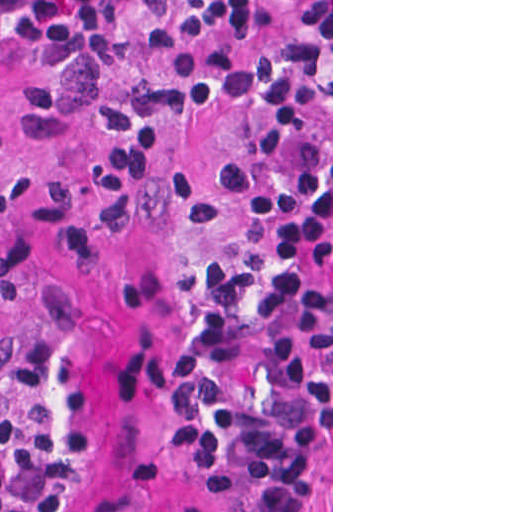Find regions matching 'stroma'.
I'll list each match as a JSON object with an SVG mask.
<instances>
[{
	"mask_svg": "<svg viewBox=\"0 0 512 512\" xmlns=\"http://www.w3.org/2000/svg\"><path fill=\"white\" fill-rule=\"evenodd\" d=\"M16 1L0 0V11ZM283 33L321 51L331 113V438L314 460L302 512H333V0H291L250 48L213 51L186 67L161 175L121 232L22 246L0 260V360L28 333L53 331L70 379L103 407L57 512H219L206 479L184 471L165 445L170 336L202 274L240 254L254 141L235 105L237 58ZM100 127L98 76L37 70L0 89V157L27 172L76 170Z\"/></svg>",
	"mask_w": 512,
	"mask_h": 512,
	"instance_id": "stroma-1",
	"label": "stroma"
}]
</instances>
